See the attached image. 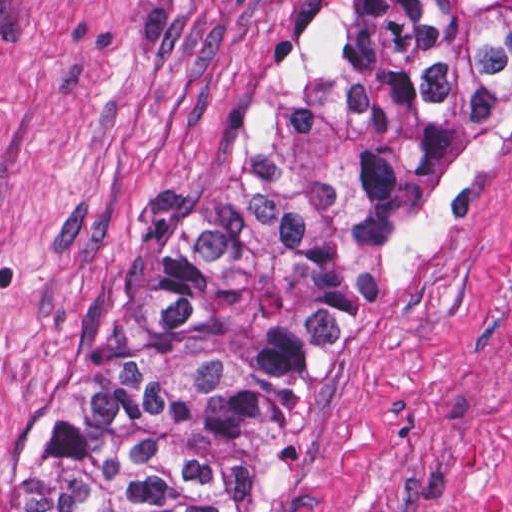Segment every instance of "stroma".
I'll list each match as a JSON object with an SVG mask.
<instances>
[{
	"instance_id": "1",
	"label": "stroma",
	"mask_w": 512,
	"mask_h": 512,
	"mask_svg": "<svg viewBox=\"0 0 512 512\" xmlns=\"http://www.w3.org/2000/svg\"><path fill=\"white\" fill-rule=\"evenodd\" d=\"M348 1L0 0V469ZM277 512H512V117L342 354Z\"/></svg>"
}]
</instances>
